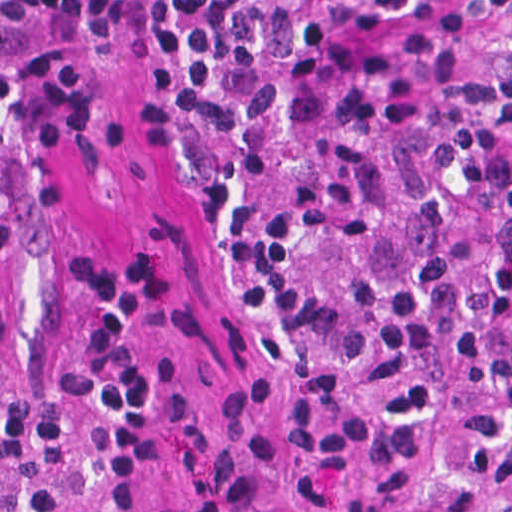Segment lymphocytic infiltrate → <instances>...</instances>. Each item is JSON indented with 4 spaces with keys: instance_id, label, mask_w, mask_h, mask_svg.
Returning <instances> with one entry per match:
<instances>
[{
    "instance_id": "1",
    "label": "lymphocytic infiltrate",
    "mask_w": 512,
    "mask_h": 512,
    "mask_svg": "<svg viewBox=\"0 0 512 512\" xmlns=\"http://www.w3.org/2000/svg\"><path fill=\"white\" fill-rule=\"evenodd\" d=\"M146 136L180 144L247 294L318 374L291 438L334 512H420L433 447L370 391L405 358L492 377L463 463L512 512V0H137ZM83 165L0 179V466L31 512H147L175 470L190 512H282V433L253 378L180 388L162 335L181 281L153 255L67 280V388L24 363L51 257L93 203Z\"/></svg>"
}]
</instances>
